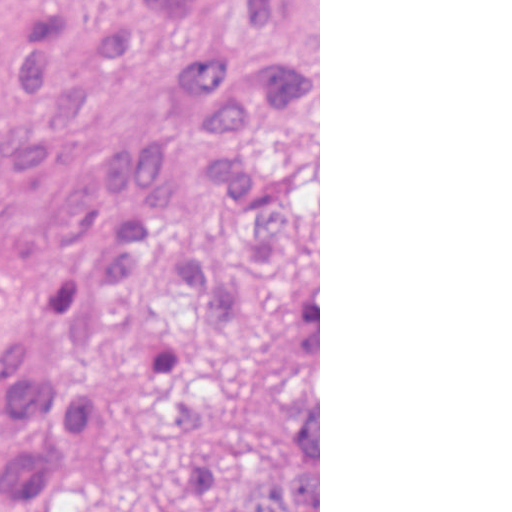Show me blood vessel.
<instances>
[{
	"instance_id": "8fb6f2fc",
	"label": "blood vessel",
	"mask_w": 512,
	"mask_h": 512,
	"mask_svg": "<svg viewBox=\"0 0 512 512\" xmlns=\"http://www.w3.org/2000/svg\"><path fill=\"white\" fill-rule=\"evenodd\" d=\"M148 225V190L99 171L0 219V432Z\"/></svg>"
}]
</instances>
